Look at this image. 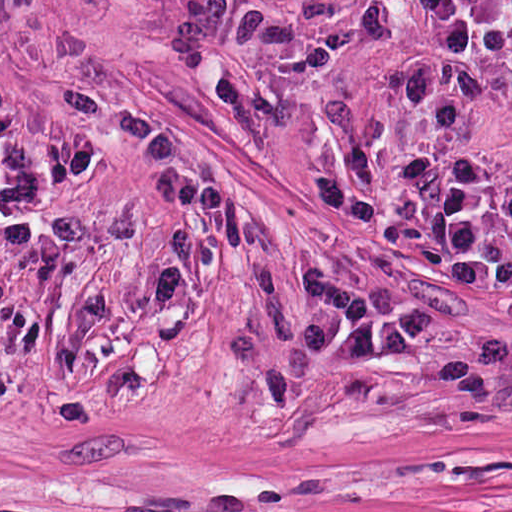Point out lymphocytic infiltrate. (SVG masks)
<instances>
[{
	"label": "lymphocytic infiltrate",
	"instance_id": "1",
	"mask_svg": "<svg viewBox=\"0 0 512 512\" xmlns=\"http://www.w3.org/2000/svg\"><path fill=\"white\" fill-rule=\"evenodd\" d=\"M422 30L476 38L512 19V0H400Z\"/></svg>",
	"mask_w": 512,
	"mask_h": 512
}]
</instances>
